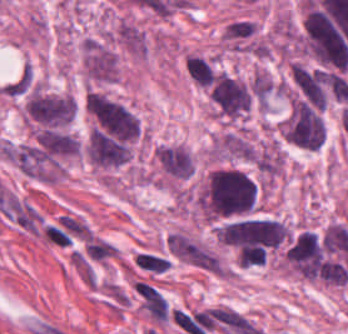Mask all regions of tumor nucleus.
Segmentation results:
<instances>
[{
  "label": "tumor nucleus",
  "mask_w": 348,
  "mask_h": 334,
  "mask_svg": "<svg viewBox=\"0 0 348 334\" xmlns=\"http://www.w3.org/2000/svg\"><path fill=\"white\" fill-rule=\"evenodd\" d=\"M258 185L242 169L224 166L208 173L198 196L199 213L212 220L242 217L255 210Z\"/></svg>",
  "instance_id": "tumor-nucleus-1"
},
{
  "label": "tumor nucleus",
  "mask_w": 348,
  "mask_h": 334,
  "mask_svg": "<svg viewBox=\"0 0 348 334\" xmlns=\"http://www.w3.org/2000/svg\"><path fill=\"white\" fill-rule=\"evenodd\" d=\"M25 114L41 139L66 131L76 104L71 95L40 84H33L23 101Z\"/></svg>",
  "instance_id": "tumor-nucleus-2"
},
{
  "label": "tumor nucleus",
  "mask_w": 348,
  "mask_h": 334,
  "mask_svg": "<svg viewBox=\"0 0 348 334\" xmlns=\"http://www.w3.org/2000/svg\"><path fill=\"white\" fill-rule=\"evenodd\" d=\"M279 136L305 149H314L323 140L321 109L307 100L292 96L277 126Z\"/></svg>",
  "instance_id": "tumor-nucleus-3"
},
{
  "label": "tumor nucleus",
  "mask_w": 348,
  "mask_h": 334,
  "mask_svg": "<svg viewBox=\"0 0 348 334\" xmlns=\"http://www.w3.org/2000/svg\"><path fill=\"white\" fill-rule=\"evenodd\" d=\"M209 95L218 113L226 119H240L250 108L247 80L220 69L211 84Z\"/></svg>",
  "instance_id": "tumor-nucleus-4"
},
{
  "label": "tumor nucleus",
  "mask_w": 348,
  "mask_h": 334,
  "mask_svg": "<svg viewBox=\"0 0 348 334\" xmlns=\"http://www.w3.org/2000/svg\"><path fill=\"white\" fill-rule=\"evenodd\" d=\"M154 157L168 176L187 179L194 170L189 150L175 144L159 145Z\"/></svg>",
  "instance_id": "tumor-nucleus-5"
},
{
  "label": "tumor nucleus",
  "mask_w": 348,
  "mask_h": 334,
  "mask_svg": "<svg viewBox=\"0 0 348 334\" xmlns=\"http://www.w3.org/2000/svg\"><path fill=\"white\" fill-rule=\"evenodd\" d=\"M184 66L189 78L197 85L209 87L217 72L212 61L197 54H189Z\"/></svg>",
  "instance_id": "tumor-nucleus-6"
}]
</instances>
